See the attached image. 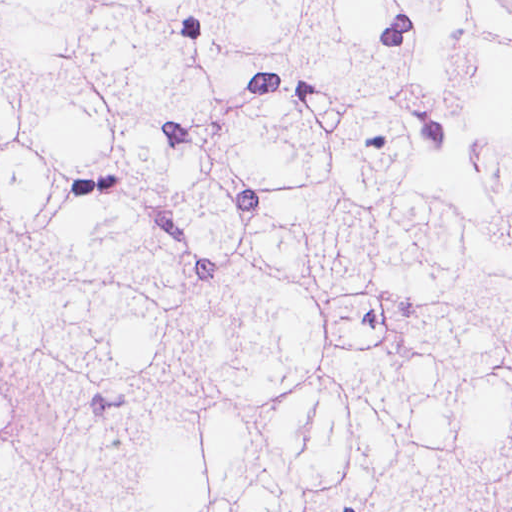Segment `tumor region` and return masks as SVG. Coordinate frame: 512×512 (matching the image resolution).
<instances>
[{
  "label": "tumor region",
  "mask_w": 512,
  "mask_h": 512,
  "mask_svg": "<svg viewBox=\"0 0 512 512\" xmlns=\"http://www.w3.org/2000/svg\"><path fill=\"white\" fill-rule=\"evenodd\" d=\"M0 512H512V1H0Z\"/></svg>",
  "instance_id": "e687c5a6"
}]
</instances>
